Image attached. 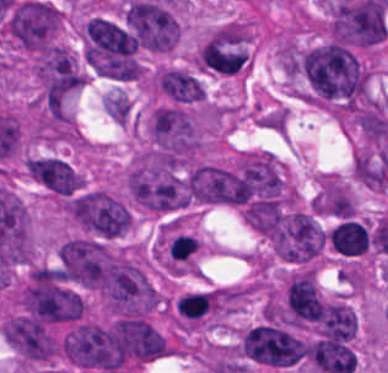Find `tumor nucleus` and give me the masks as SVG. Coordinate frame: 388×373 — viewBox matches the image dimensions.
<instances>
[{
    "instance_id": "1",
    "label": "tumor nucleus",
    "mask_w": 388,
    "mask_h": 373,
    "mask_svg": "<svg viewBox=\"0 0 388 373\" xmlns=\"http://www.w3.org/2000/svg\"><path fill=\"white\" fill-rule=\"evenodd\" d=\"M298 98L332 114L345 115L366 95L368 67L357 51L322 43L301 51L296 61Z\"/></svg>"
},
{
    "instance_id": "2",
    "label": "tumor nucleus",
    "mask_w": 388,
    "mask_h": 373,
    "mask_svg": "<svg viewBox=\"0 0 388 373\" xmlns=\"http://www.w3.org/2000/svg\"><path fill=\"white\" fill-rule=\"evenodd\" d=\"M185 201L209 205H240L244 199L242 161L198 159L182 176Z\"/></svg>"
},
{
    "instance_id": "3",
    "label": "tumor nucleus",
    "mask_w": 388,
    "mask_h": 373,
    "mask_svg": "<svg viewBox=\"0 0 388 373\" xmlns=\"http://www.w3.org/2000/svg\"><path fill=\"white\" fill-rule=\"evenodd\" d=\"M239 352L253 363L287 367L306 357V344L290 326L260 322L241 330Z\"/></svg>"
},
{
    "instance_id": "4",
    "label": "tumor nucleus",
    "mask_w": 388,
    "mask_h": 373,
    "mask_svg": "<svg viewBox=\"0 0 388 373\" xmlns=\"http://www.w3.org/2000/svg\"><path fill=\"white\" fill-rule=\"evenodd\" d=\"M197 70L233 76L249 66V32L244 23L228 21L205 35L196 52Z\"/></svg>"
},
{
    "instance_id": "5",
    "label": "tumor nucleus",
    "mask_w": 388,
    "mask_h": 373,
    "mask_svg": "<svg viewBox=\"0 0 388 373\" xmlns=\"http://www.w3.org/2000/svg\"><path fill=\"white\" fill-rule=\"evenodd\" d=\"M265 238L272 252L280 259L303 262L320 249L324 235L308 213L286 211L266 232Z\"/></svg>"
},
{
    "instance_id": "6",
    "label": "tumor nucleus",
    "mask_w": 388,
    "mask_h": 373,
    "mask_svg": "<svg viewBox=\"0 0 388 373\" xmlns=\"http://www.w3.org/2000/svg\"><path fill=\"white\" fill-rule=\"evenodd\" d=\"M72 217L84 229L112 238L128 228L131 216L110 191L94 189L72 199Z\"/></svg>"
},
{
    "instance_id": "7",
    "label": "tumor nucleus",
    "mask_w": 388,
    "mask_h": 373,
    "mask_svg": "<svg viewBox=\"0 0 388 373\" xmlns=\"http://www.w3.org/2000/svg\"><path fill=\"white\" fill-rule=\"evenodd\" d=\"M32 177L47 191L57 195H75L85 187L83 173L69 161L42 153L29 157Z\"/></svg>"
},
{
    "instance_id": "8",
    "label": "tumor nucleus",
    "mask_w": 388,
    "mask_h": 373,
    "mask_svg": "<svg viewBox=\"0 0 388 373\" xmlns=\"http://www.w3.org/2000/svg\"><path fill=\"white\" fill-rule=\"evenodd\" d=\"M309 205L316 213L352 217L355 200L348 187L335 172L314 174Z\"/></svg>"
},
{
    "instance_id": "9",
    "label": "tumor nucleus",
    "mask_w": 388,
    "mask_h": 373,
    "mask_svg": "<svg viewBox=\"0 0 388 373\" xmlns=\"http://www.w3.org/2000/svg\"><path fill=\"white\" fill-rule=\"evenodd\" d=\"M327 238L333 251L341 255L363 253L368 245L366 226L352 218H345L328 231Z\"/></svg>"
}]
</instances>
